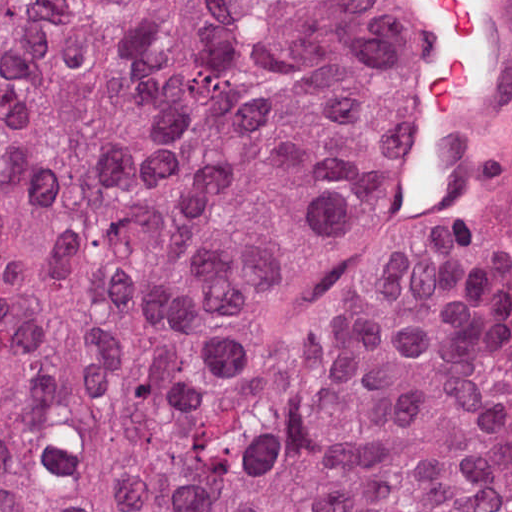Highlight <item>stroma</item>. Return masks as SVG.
<instances>
[{"label":"stroma","instance_id":"stroma-1","mask_svg":"<svg viewBox=\"0 0 512 512\" xmlns=\"http://www.w3.org/2000/svg\"><path fill=\"white\" fill-rule=\"evenodd\" d=\"M406 37V59L379 85L384 130L482 149L512 170V0H476L470 53L473 82L459 124L435 125L421 96L431 81L453 17L437 0H380ZM512 512V337L510 334V468L506 511Z\"/></svg>","mask_w":512,"mask_h":512}]
</instances>
